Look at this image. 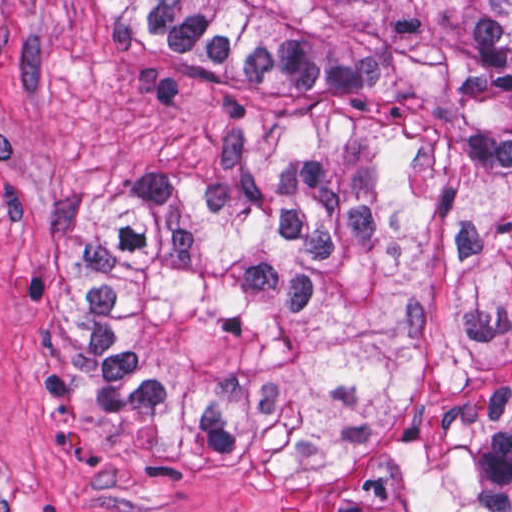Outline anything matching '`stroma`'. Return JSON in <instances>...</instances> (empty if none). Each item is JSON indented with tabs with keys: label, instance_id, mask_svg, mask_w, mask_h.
Listing matches in <instances>:
<instances>
[{
	"label": "stroma",
	"instance_id": "obj_1",
	"mask_svg": "<svg viewBox=\"0 0 512 512\" xmlns=\"http://www.w3.org/2000/svg\"><path fill=\"white\" fill-rule=\"evenodd\" d=\"M295 133L215 106L108 0H0V512H328L288 470L112 454L33 381L49 280L83 199Z\"/></svg>",
	"mask_w": 512,
	"mask_h": 512
}]
</instances>
